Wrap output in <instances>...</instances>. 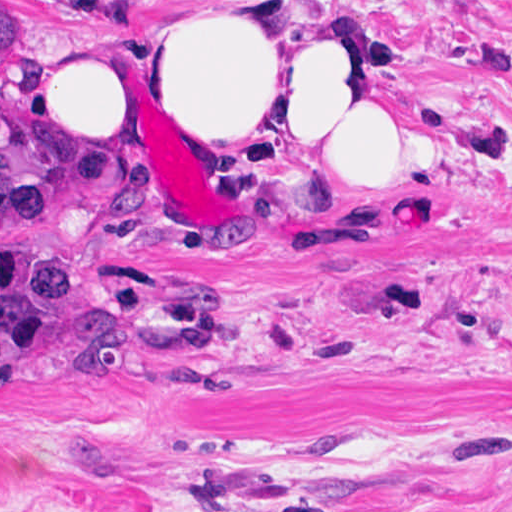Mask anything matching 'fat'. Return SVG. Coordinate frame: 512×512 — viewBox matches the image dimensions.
Masks as SVG:
<instances>
[{"label": "fat", "instance_id": "1", "mask_svg": "<svg viewBox=\"0 0 512 512\" xmlns=\"http://www.w3.org/2000/svg\"><path fill=\"white\" fill-rule=\"evenodd\" d=\"M89 11L114 0L39 1ZM116 43L52 66L34 132L81 174L153 157L154 128L184 110H237L271 142L312 136L290 168L351 178H416L470 162L473 145L399 123L357 88L349 54L281 0L174 11Z\"/></svg>", "mask_w": 512, "mask_h": 512}]
</instances>
